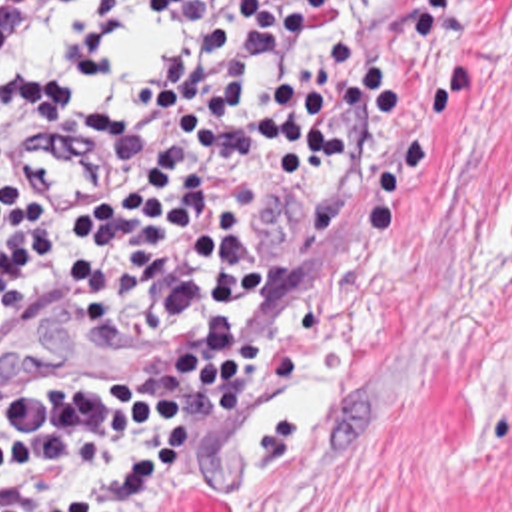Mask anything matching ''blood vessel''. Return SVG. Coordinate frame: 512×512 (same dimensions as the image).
Masks as SVG:
<instances>
[{
  "label": "blood vessel",
  "instance_id": "obj_1",
  "mask_svg": "<svg viewBox=\"0 0 512 512\" xmlns=\"http://www.w3.org/2000/svg\"><path fill=\"white\" fill-rule=\"evenodd\" d=\"M95 137L53 123L27 129L11 167L19 207L45 217H85L109 203L121 179V149Z\"/></svg>",
  "mask_w": 512,
  "mask_h": 512
}]
</instances>
